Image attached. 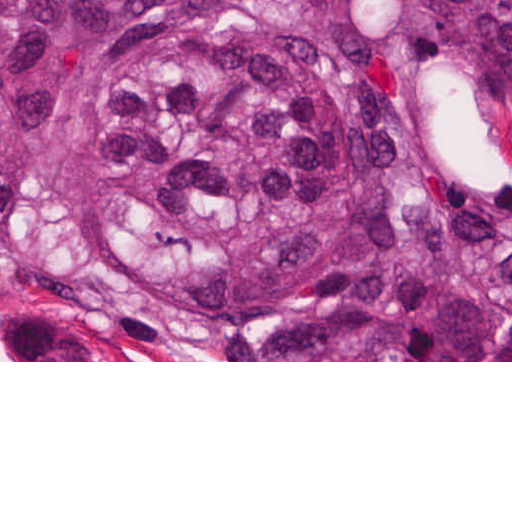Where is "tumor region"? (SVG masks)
Returning <instances> with one entry per match:
<instances>
[{
    "mask_svg": "<svg viewBox=\"0 0 512 512\" xmlns=\"http://www.w3.org/2000/svg\"><path fill=\"white\" fill-rule=\"evenodd\" d=\"M0 274L155 358L512 360V0H0Z\"/></svg>",
    "mask_w": 512,
    "mask_h": 512,
    "instance_id": "e687c5a6",
    "label": "tumor region"
}]
</instances>
